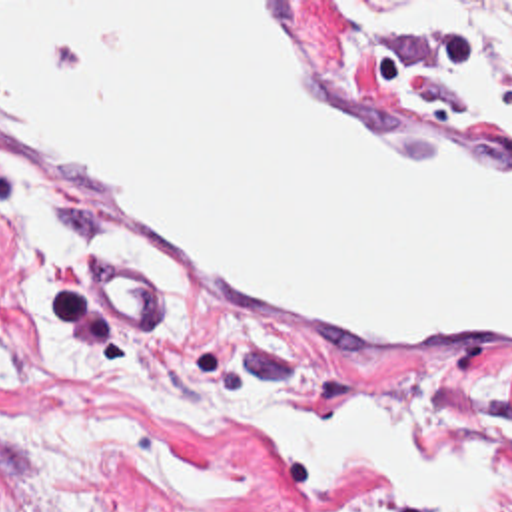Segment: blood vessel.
Masks as SVG:
<instances>
[{"label":"blood vessel","instance_id":"1","mask_svg":"<svg viewBox=\"0 0 512 512\" xmlns=\"http://www.w3.org/2000/svg\"><path fill=\"white\" fill-rule=\"evenodd\" d=\"M0 166L195 296L512 389V120L372 90L318 2H0Z\"/></svg>","mask_w":512,"mask_h":512}]
</instances>
